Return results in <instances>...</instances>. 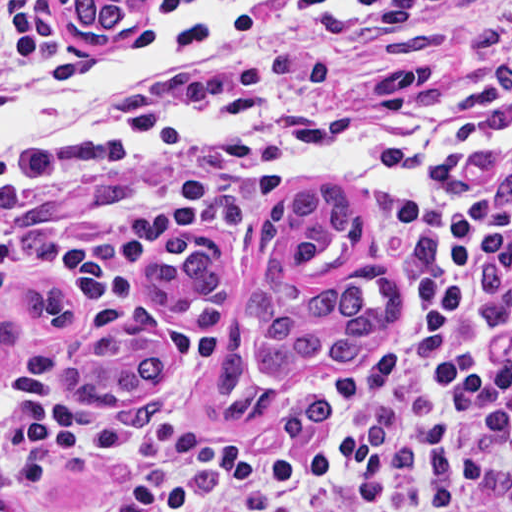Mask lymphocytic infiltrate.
<instances>
[{"mask_svg":"<svg viewBox=\"0 0 512 512\" xmlns=\"http://www.w3.org/2000/svg\"><path fill=\"white\" fill-rule=\"evenodd\" d=\"M78 55L35 25L0 31V97L55 87ZM434 84L426 137L483 155L424 170L406 217L402 274L411 323L336 419L260 454L209 464L151 428L65 425V447L137 465L173 485L187 512H512V0H292L267 57L199 108L215 120L309 101L392 98L398 77ZM212 173L156 197L125 230L23 257L0 206V284L48 269L84 296L79 330L0 391L40 413L97 337L107 302L128 295L160 320L190 369L211 368L219 335L141 293L148 252L220 206Z\"/></svg>","mask_w":512,"mask_h":512,"instance_id":"f902f5d3","label":"lymphocytic infiltrate"}]
</instances>
